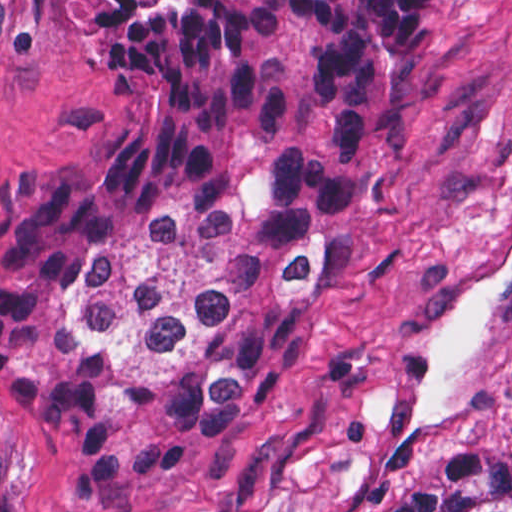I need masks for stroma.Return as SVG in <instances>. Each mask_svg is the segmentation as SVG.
<instances>
[{
  "label": "stroma",
  "mask_w": 512,
  "mask_h": 512,
  "mask_svg": "<svg viewBox=\"0 0 512 512\" xmlns=\"http://www.w3.org/2000/svg\"><path fill=\"white\" fill-rule=\"evenodd\" d=\"M429 97L345 272L262 372L224 451L97 506L0 385V512H367L436 443L512 455V0H425ZM123 62L75 0H0V193L119 144Z\"/></svg>",
  "instance_id": "stroma-1"
}]
</instances>
